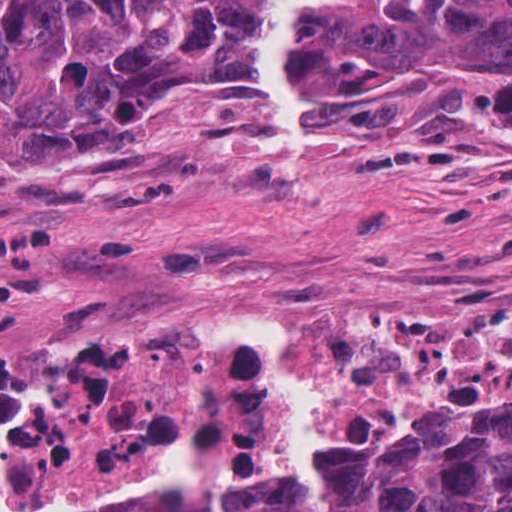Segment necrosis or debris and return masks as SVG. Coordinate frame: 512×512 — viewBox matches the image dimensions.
Here are the masks:
<instances>
[{
    "instance_id": "necrosis-or-debris-1",
    "label": "necrosis or debris",
    "mask_w": 512,
    "mask_h": 512,
    "mask_svg": "<svg viewBox=\"0 0 512 512\" xmlns=\"http://www.w3.org/2000/svg\"><path fill=\"white\" fill-rule=\"evenodd\" d=\"M241 324L290 334L291 374L318 397L322 433L370 428L407 392L512 357V310L451 308L166 320L57 355L2 357L0 509L109 477L146 432L175 433L200 387L226 391L223 434L285 435L283 397L261 357L220 339Z\"/></svg>"
}]
</instances>
